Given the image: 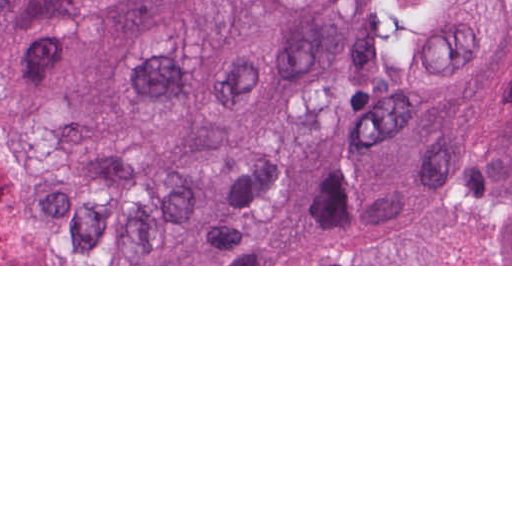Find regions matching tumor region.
Returning <instances> with one entry per match:
<instances>
[{"mask_svg":"<svg viewBox=\"0 0 512 512\" xmlns=\"http://www.w3.org/2000/svg\"><path fill=\"white\" fill-rule=\"evenodd\" d=\"M0 264H512V0H0Z\"/></svg>","mask_w":512,"mask_h":512,"instance_id":"e687c5a6","label":"tumor region"}]
</instances>
